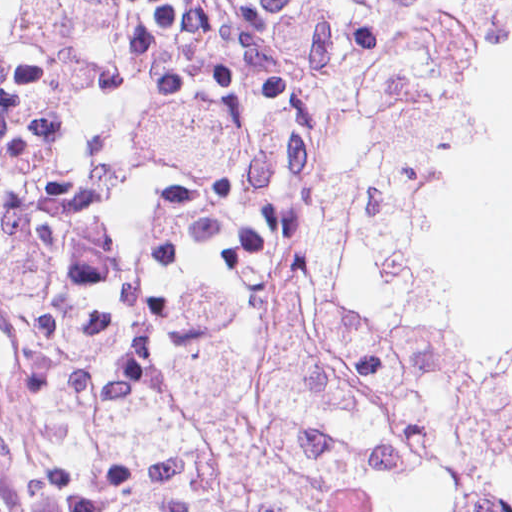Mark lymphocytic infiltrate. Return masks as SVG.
I'll list each match as a JSON object with an SVG mask.
<instances>
[{
	"label": "lymphocytic infiltrate",
	"instance_id": "lymphocytic-infiltrate-1",
	"mask_svg": "<svg viewBox=\"0 0 512 512\" xmlns=\"http://www.w3.org/2000/svg\"><path fill=\"white\" fill-rule=\"evenodd\" d=\"M412 0H0V274L50 366L219 303Z\"/></svg>",
	"mask_w": 512,
	"mask_h": 512
}]
</instances>
